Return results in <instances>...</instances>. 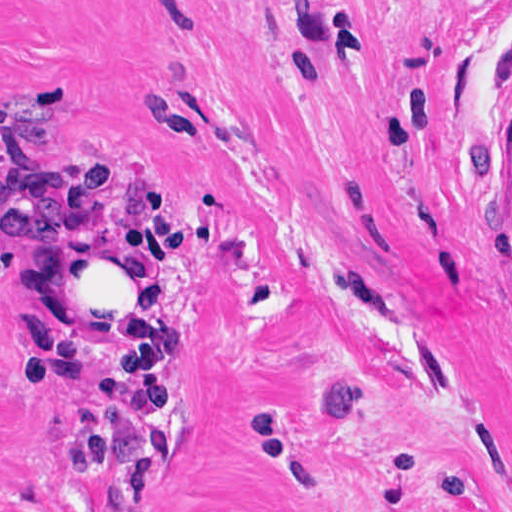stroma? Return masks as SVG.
Listing matches in <instances>:
<instances>
[{
    "label": "stroma",
    "mask_w": 512,
    "mask_h": 512,
    "mask_svg": "<svg viewBox=\"0 0 512 512\" xmlns=\"http://www.w3.org/2000/svg\"><path fill=\"white\" fill-rule=\"evenodd\" d=\"M105 234L132 375L41 305ZM0 512H512V0H0Z\"/></svg>",
    "instance_id": "stroma-1"
}]
</instances>
